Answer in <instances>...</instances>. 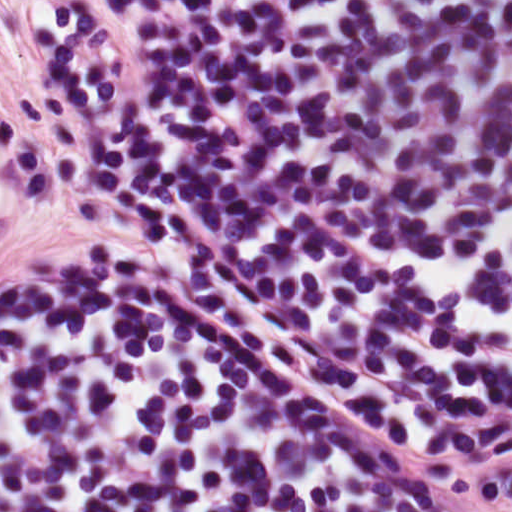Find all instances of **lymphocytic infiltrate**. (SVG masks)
<instances>
[{"mask_svg": "<svg viewBox=\"0 0 512 512\" xmlns=\"http://www.w3.org/2000/svg\"><path fill=\"white\" fill-rule=\"evenodd\" d=\"M20 188L0 117V226ZM0 512H229L118 261L0 292Z\"/></svg>", "mask_w": 512, "mask_h": 512, "instance_id": "lymphocytic-infiltrate-1", "label": "lymphocytic infiltrate"}]
</instances>
